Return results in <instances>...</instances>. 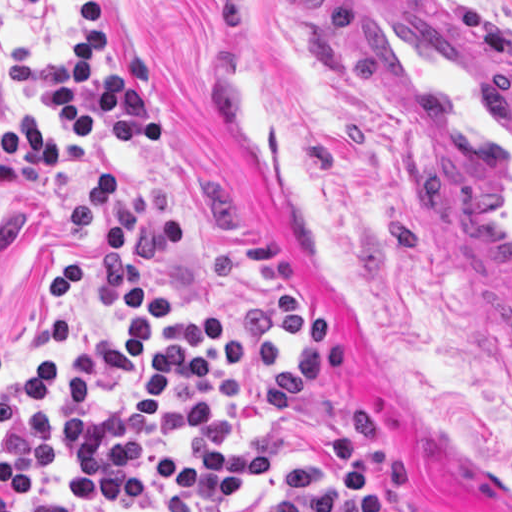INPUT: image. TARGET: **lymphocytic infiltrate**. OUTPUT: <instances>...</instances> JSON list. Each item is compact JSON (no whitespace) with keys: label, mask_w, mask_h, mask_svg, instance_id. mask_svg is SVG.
<instances>
[{"label":"lymphocytic infiltrate","mask_w":512,"mask_h":512,"mask_svg":"<svg viewBox=\"0 0 512 512\" xmlns=\"http://www.w3.org/2000/svg\"><path fill=\"white\" fill-rule=\"evenodd\" d=\"M13 8H38L66 32L60 58L36 61L22 44L9 57V82L49 105L52 122L74 141L30 112L0 127V193L47 172L82 183L67 206V225L83 242L98 245L103 279L121 312L118 336L88 334L71 362L54 349L40 353L36 382L3 375L8 365L0 343V512H79L61 501L28 502L56 461L58 443L48 402L67 404L85 416L94 404L92 373L126 385L132 435L118 464L81 472L88 505H129L143 500L155 478L174 495L205 509L245 501L270 478L273 454L263 449L203 451L169 443L182 426L209 421L218 396L196 395L177 419L167 418L176 385L214 380L218 364L239 377L278 368L279 354L259 341L231 339L223 319L173 314V300L136 264L138 251L183 253L186 224L170 215V191L158 183L126 192L109 167L77 169L92 157L89 143L105 140L132 153L166 136L161 110L147 96L154 57L130 54L129 70L100 65L104 47L103 0H0ZM2 47L0 45V57ZM132 512H138L136 510Z\"/></svg>","instance_id":"1"}]
</instances>
